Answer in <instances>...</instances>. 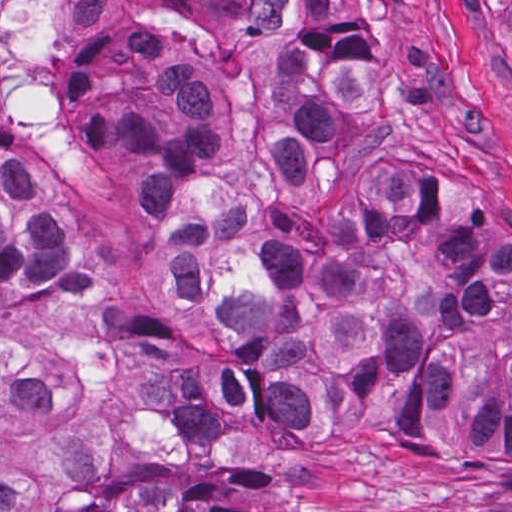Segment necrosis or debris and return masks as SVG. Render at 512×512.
<instances>
[{"instance_id": "1", "label": "necrosis or debris", "mask_w": 512, "mask_h": 512, "mask_svg": "<svg viewBox=\"0 0 512 512\" xmlns=\"http://www.w3.org/2000/svg\"><path fill=\"white\" fill-rule=\"evenodd\" d=\"M93 0H79L68 42L19 126L11 133L0 95V144L27 153H62L78 138L69 113V40ZM6 0H0V9Z\"/></svg>"}]
</instances>
